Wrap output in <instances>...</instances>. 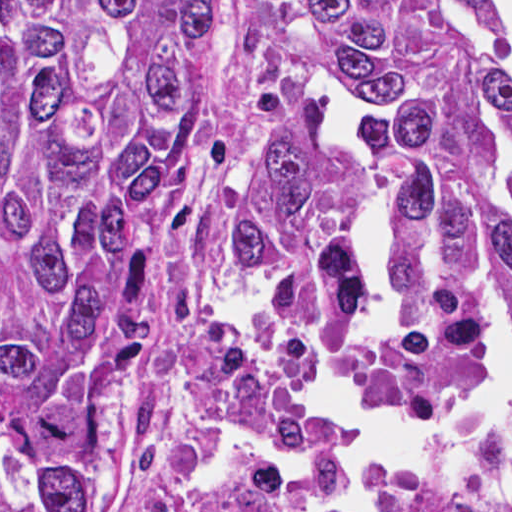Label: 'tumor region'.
I'll use <instances>...</instances> for the list:
<instances>
[{
  "mask_svg": "<svg viewBox=\"0 0 512 512\" xmlns=\"http://www.w3.org/2000/svg\"><path fill=\"white\" fill-rule=\"evenodd\" d=\"M318 60L373 103L392 338L357 382L417 399L493 364L512 313V63L481 0H1V512H182L233 439L329 462L333 422L239 321L311 337L360 301L356 213ZM512 471V425L479 439ZM209 512H303L245 486ZM378 512H480L409 478Z\"/></svg>",
  "mask_w": 512,
  "mask_h": 512,
  "instance_id": "e687c5a6",
  "label": "tumor region"
}]
</instances>
